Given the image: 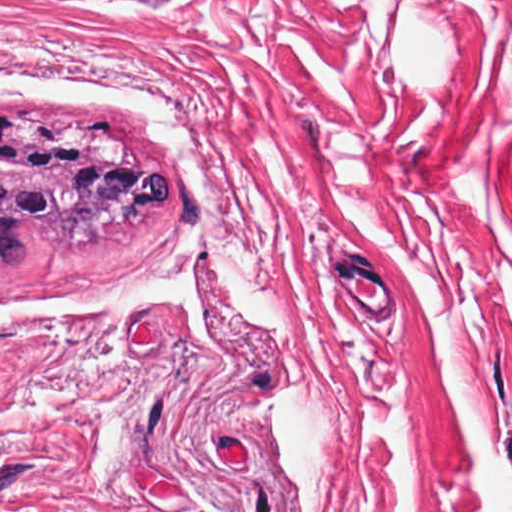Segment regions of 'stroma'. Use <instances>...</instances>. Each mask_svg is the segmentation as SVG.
Listing matches in <instances>:
<instances>
[{
    "label": "stroma",
    "mask_w": 512,
    "mask_h": 512,
    "mask_svg": "<svg viewBox=\"0 0 512 512\" xmlns=\"http://www.w3.org/2000/svg\"><path fill=\"white\" fill-rule=\"evenodd\" d=\"M0 512H512V356L0 302Z\"/></svg>",
    "instance_id": "obj_1"
}]
</instances>
